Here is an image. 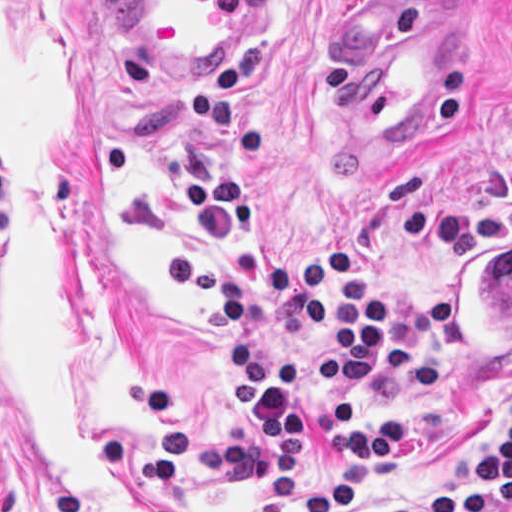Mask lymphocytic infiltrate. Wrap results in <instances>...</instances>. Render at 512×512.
<instances>
[{
    "mask_svg": "<svg viewBox=\"0 0 512 512\" xmlns=\"http://www.w3.org/2000/svg\"><path fill=\"white\" fill-rule=\"evenodd\" d=\"M191 195L220 240L276 286L293 321L319 334V362L277 360L264 346L257 297L206 249L172 248L162 261L167 293L204 305L232 335V380L253 424V469L271 488L273 512H290L302 457L320 427L324 458L337 472L326 475L312 495L311 512H347L355 502L353 467L379 479L402 445V418L392 410L365 408V383L392 312L373 299V282L363 271L342 285L330 281L351 262V249L342 241L328 244L310 266H285L265 243L249 191L191 176ZM509 501L512 419L480 474L454 495L392 512H487Z\"/></svg>",
    "mask_w": 512,
    "mask_h": 512,
    "instance_id": "obj_1",
    "label": "lymphocytic infiltrate"
}]
</instances>
